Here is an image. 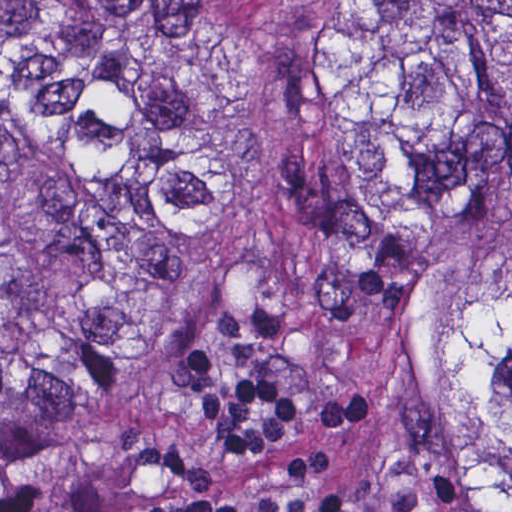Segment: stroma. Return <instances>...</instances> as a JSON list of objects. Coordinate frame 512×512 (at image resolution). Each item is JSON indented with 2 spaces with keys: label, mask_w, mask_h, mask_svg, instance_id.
I'll return each instance as SVG.
<instances>
[{
  "label": "stroma",
  "mask_w": 512,
  "mask_h": 512,
  "mask_svg": "<svg viewBox=\"0 0 512 512\" xmlns=\"http://www.w3.org/2000/svg\"><path fill=\"white\" fill-rule=\"evenodd\" d=\"M0 1H512V0H0ZM246 305H267L288 321L280 350L267 360L270 377L303 398V421L283 441L248 464L212 452L199 400L170 374L172 357L196 337L221 373L243 364L218 327L219 318ZM346 393L335 344L323 318L302 298L275 287L197 288L170 303L47 429L35 447L0 476V499L38 484H82L121 450L116 440L136 430L173 441L213 473V484L193 485L155 466H143L111 487L110 512H146L165 498L255 497L288 493L289 465L318 445L320 402ZM376 408V395H375ZM310 493H336L343 512H364L358 476L347 451V426L332 432L326 466Z\"/></svg>",
  "instance_id": "35a3bbf8"
}]
</instances>
